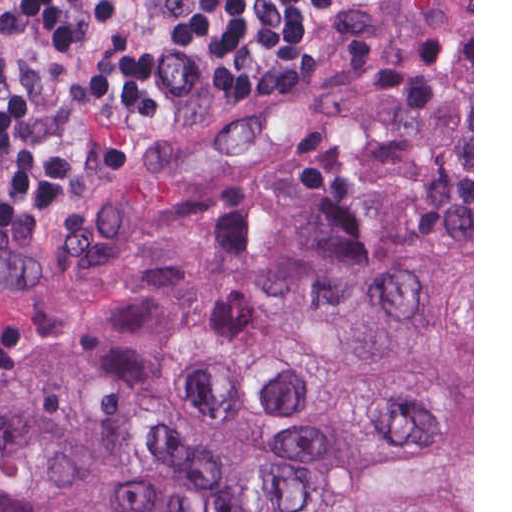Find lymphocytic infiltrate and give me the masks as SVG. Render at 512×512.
I'll use <instances>...</instances> for the list:
<instances>
[{
  "label": "lymphocytic infiltrate",
  "instance_id": "f902f5d3",
  "mask_svg": "<svg viewBox=\"0 0 512 512\" xmlns=\"http://www.w3.org/2000/svg\"><path fill=\"white\" fill-rule=\"evenodd\" d=\"M359 0H2L0 189L121 167L199 77L274 82Z\"/></svg>",
  "mask_w": 512,
  "mask_h": 512
}]
</instances>
